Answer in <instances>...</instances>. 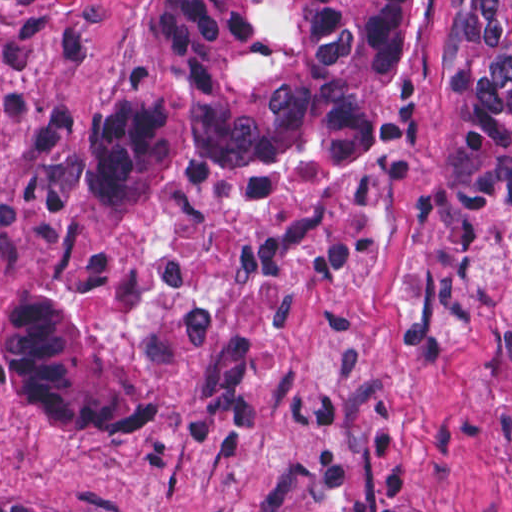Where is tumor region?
Segmentation results:
<instances>
[{"instance_id": "obj_1", "label": "tumor region", "mask_w": 512, "mask_h": 512, "mask_svg": "<svg viewBox=\"0 0 512 512\" xmlns=\"http://www.w3.org/2000/svg\"><path fill=\"white\" fill-rule=\"evenodd\" d=\"M410 1L143 0L131 50L147 77L89 173L99 258L24 297L0 330V367L28 410L66 433H153L164 419L116 344L109 279L125 225L168 191L238 182L296 204L416 166L439 196L444 262L498 247L512 229V0H462L460 111L433 162L415 159L398 114ZM0 512L73 511L0 489Z\"/></svg>"}]
</instances>
